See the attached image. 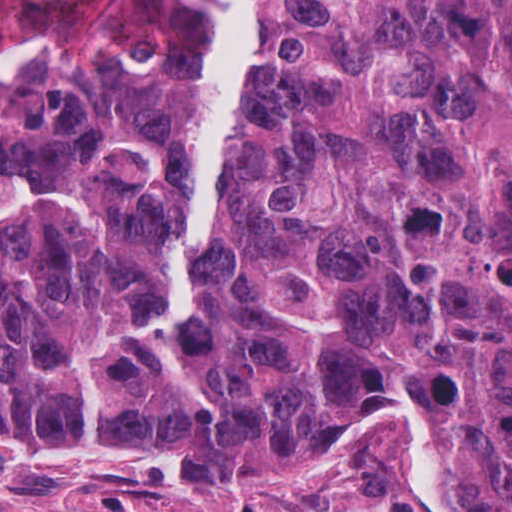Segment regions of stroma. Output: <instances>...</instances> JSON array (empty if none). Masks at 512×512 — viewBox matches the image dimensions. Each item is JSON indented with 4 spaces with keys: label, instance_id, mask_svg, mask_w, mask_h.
Listing matches in <instances>:
<instances>
[{
    "label": "stroma",
    "instance_id": "35a3bbf8",
    "mask_svg": "<svg viewBox=\"0 0 512 512\" xmlns=\"http://www.w3.org/2000/svg\"><path fill=\"white\" fill-rule=\"evenodd\" d=\"M421 415L438 441L447 509L460 512L442 431ZM0 512L421 511L389 416L353 440L343 462L289 482L196 477L153 450L54 445L0 428Z\"/></svg>",
    "mask_w": 512,
    "mask_h": 512
}]
</instances>
